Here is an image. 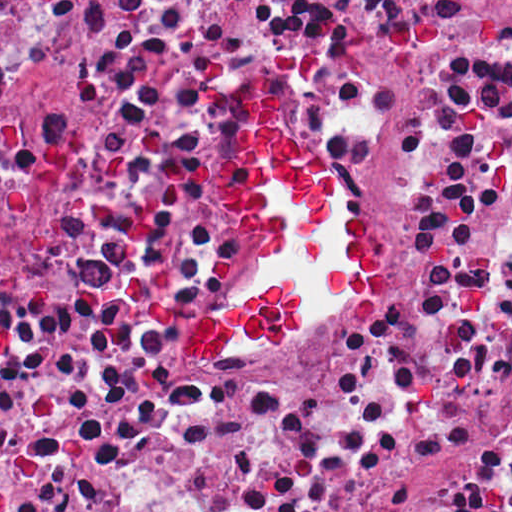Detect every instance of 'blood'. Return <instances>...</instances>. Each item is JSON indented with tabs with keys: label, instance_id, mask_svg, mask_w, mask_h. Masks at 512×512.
Returning <instances> with one entry per match:
<instances>
[{
	"label": "blood",
	"instance_id": "blood-1",
	"mask_svg": "<svg viewBox=\"0 0 512 512\" xmlns=\"http://www.w3.org/2000/svg\"><path fill=\"white\" fill-rule=\"evenodd\" d=\"M242 96L250 122L207 172L235 220L264 232L267 272L188 327L184 351L199 363H213L244 339L291 346L303 326V296L293 283L302 272L331 280L348 300L377 303L376 231L355 206L343 248L332 256L322 246L319 231L336 204L339 174L300 147L287 120V86L259 72Z\"/></svg>",
	"mask_w": 512,
	"mask_h": 512
}]
</instances>
